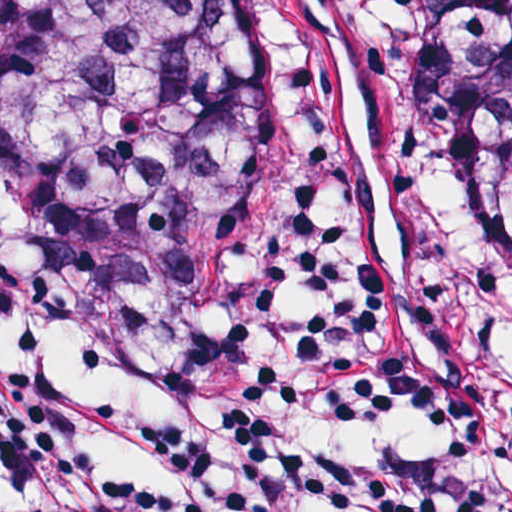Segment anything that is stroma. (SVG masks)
<instances>
[{"instance_id":"1","label":"stroma","mask_w":512,"mask_h":512,"mask_svg":"<svg viewBox=\"0 0 512 512\" xmlns=\"http://www.w3.org/2000/svg\"><path fill=\"white\" fill-rule=\"evenodd\" d=\"M414 0H251V197L367 196L461 260L512 336V308L408 167Z\"/></svg>"}]
</instances>
